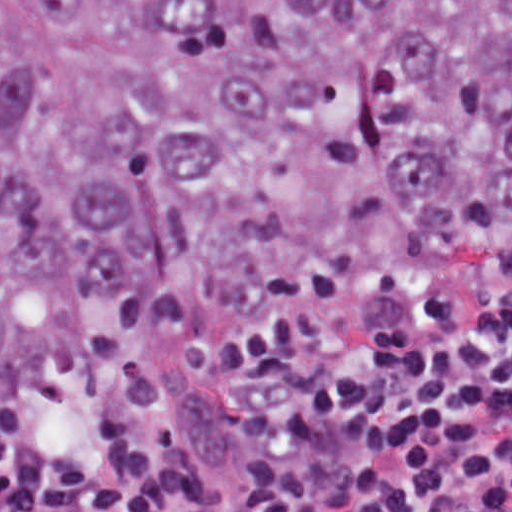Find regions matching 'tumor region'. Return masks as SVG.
<instances>
[{
	"mask_svg": "<svg viewBox=\"0 0 512 512\" xmlns=\"http://www.w3.org/2000/svg\"><path fill=\"white\" fill-rule=\"evenodd\" d=\"M473 294H512V0H0V408Z\"/></svg>",
	"mask_w": 512,
	"mask_h": 512,
	"instance_id": "e687c5a6",
	"label": "tumor region"
}]
</instances>
